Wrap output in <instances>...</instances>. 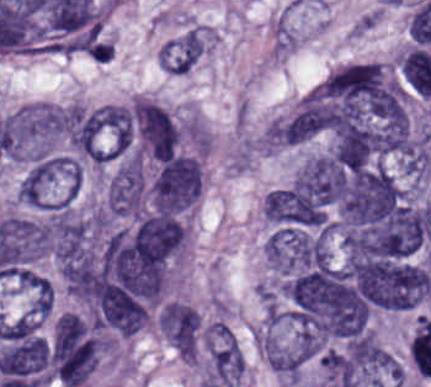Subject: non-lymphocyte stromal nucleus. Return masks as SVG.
<instances>
[{
  "instance_id": "non-lymphocyte-stromal-nucleus-1",
  "label": "non-lymphocyte stromal nucleus",
  "mask_w": 431,
  "mask_h": 387,
  "mask_svg": "<svg viewBox=\"0 0 431 387\" xmlns=\"http://www.w3.org/2000/svg\"><path fill=\"white\" fill-rule=\"evenodd\" d=\"M211 39L203 25L190 24L168 40L157 51L160 67L168 74H186L191 71Z\"/></svg>"
}]
</instances>
